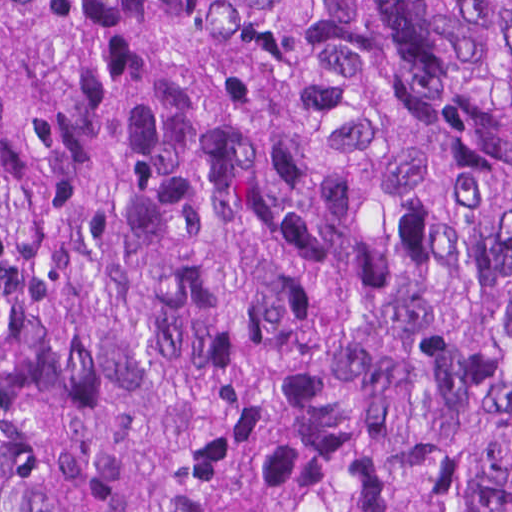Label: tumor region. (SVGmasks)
I'll return each mask as SVG.
<instances>
[{"mask_svg": "<svg viewBox=\"0 0 512 512\" xmlns=\"http://www.w3.org/2000/svg\"><path fill=\"white\" fill-rule=\"evenodd\" d=\"M0 512H512V0H0Z\"/></svg>", "mask_w": 512, "mask_h": 512, "instance_id": "obj_1", "label": "tumor region"}]
</instances>
